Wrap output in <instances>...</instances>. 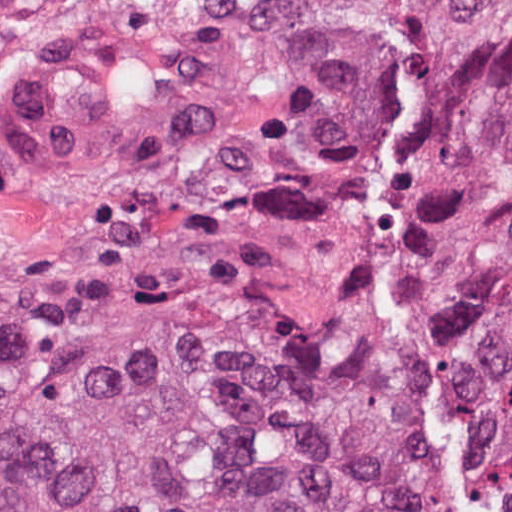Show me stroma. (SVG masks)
<instances>
[{"mask_svg": "<svg viewBox=\"0 0 512 512\" xmlns=\"http://www.w3.org/2000/svg\"><path fill=\"white\" fill-rule=\"evenodd\" d=\"M229 196L230 176L216 166H170L151 177L96 185L45 177L16 116L12 55L0 50V309L97 280L201 228ZM415 219L398 194L374 228L375 307L380 243Z\"/></svg>", "mask_w": 512, "mask_h": 512, "instance_id": "35a3bbf8", "label": "stroma"}]
</instances>
